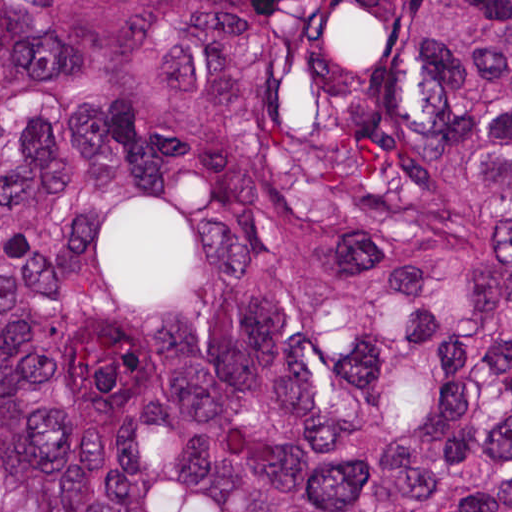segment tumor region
Instances as JSON below:
<instances>
[{
  "instance_id": "tumor-region-1",
  "label": "tumor region",
  "mask_w": 512,
  "mask_h": 512,
  "mask_svg": "<svg viewBox=\"0 0 512 512\" xmlns=\"http://www.w3.org/2000/svg\"><path fill=\"white\" fill-rule=\"evenodd\" d=\"M0 512H512V0H0Z\"/></svg>"
}]
</instances>
